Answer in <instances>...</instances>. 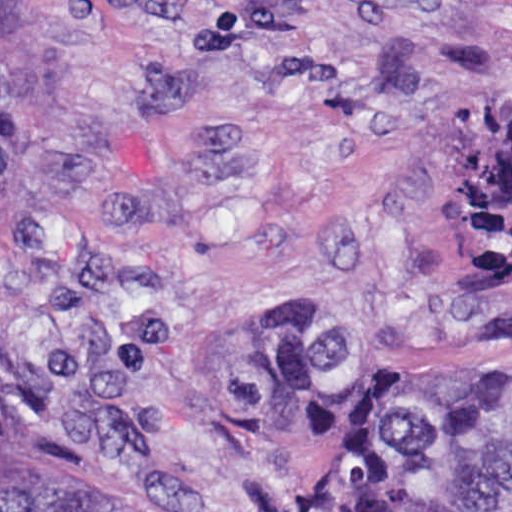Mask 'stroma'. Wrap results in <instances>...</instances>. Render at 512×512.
Wrapping results in <instances>:
<instances>
[{
    "label": "stroma",
    "mask_w": 512,
    "mask_h": 512,
    "mask_svg": "<svg viewBox=\"0 0 512 512\" xmlns=\"http://www.w3.org/2000/svg\"><path fill=\"white\" fill-rule=\"evenodd\" d=\"M512 98V0H0L3 437L116 512H317L325 422L229 413L227 322L512 360L466 266L459 120Z\"/></svg>",
    "instance_id": "1"
}]
</instances>
